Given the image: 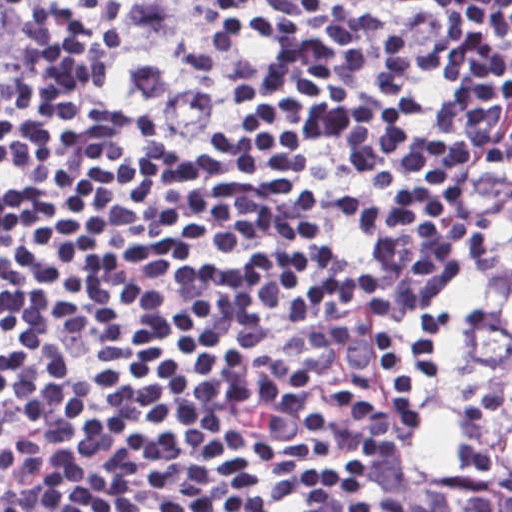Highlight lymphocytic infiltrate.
Returning <instances> with one entry per match:
<instances>
[{
	"mask_svg": "<svg viewBox=\"0 0 512 512\" xmlns=\"http://www.w3.org/2000/svg\"><path fill=\"white\" fill-rule=\"evenodd\" d=\"M33 32L0 108V512H512V0H20L0 61ZM74 57L199 125L238 80L212 162ZM504 131L458 285L370 324ZM358 326L319 418L295 357Z\"/></svg>",
	"mask_w": 512,
	"mask_h": 512,
	"instance_id": "lymphocytic-infiltrate-1",
	"label": "lymphocytic infiltrate"
}]
</instances>
